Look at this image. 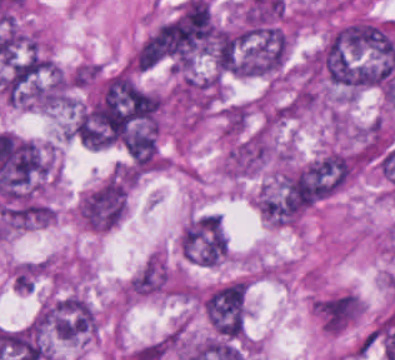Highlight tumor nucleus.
<instances>
[{
  "mask_svg": "<svg viewBox=\"0 0 395 360\" xmlns=\"http://www.w3.org/2000/svg\"><path fill=\"white\" fill-rule=\"evenodd\" d=\"M291 29L269 23L242 29L236 35L235 74L242 78H275L290 59Z\"/></svg>",
  "mask_w": 395,
  "mask_h": 360,
  "instance_id": "1",
  "label": "tumor nucleus"
},
{
  "mask_svg": "<svg viewBox=\"0 0 395 360\" xmlns=\"http://www.w3.org/2000/svg\"><path fill=\"white\" fill-rule=\"evenodd\" d=\"M201 305L216 337L243 340L246 331L247 288L245 278H237L202 292Z\"/></svg>",
  "mask_w": 395,
  "mask_h": 360,
  "instance_id": "2",
  "label": "tumor nucleus"
},
{
  "mask_svg": "<svg viewBox=\"0 0 395 360\" xmlns=\"http://www.w3.org/2000/svg\"><path fill=\"white\" fill-rule=\"evenodd\" d=\"M230 242L223 218L215 213L191 217L180 234V254L185 261L216 266L227 258Z\"/></svg>",
  "mask_w": 395,
  "mask_h": 360,
  "instance_id": "3",
  "label": "tumor nucleus"
},
{
  "mask_svg": "<svg viewBox=\"0 0 395 360\" xmlns=\"http://www.w3.org/2000/svg\"><path fill=\"white\" fill-rule=\"evenodd\" d=\"M129 184L121 179H107L82 196L80 222L96 232H109L126 215Z\"/></svg>",
  "mask_w": 395,
  "mask_h": 360,
  "instance_id": "4",
  "label": "tumor nucleus"
}]
</instances>
